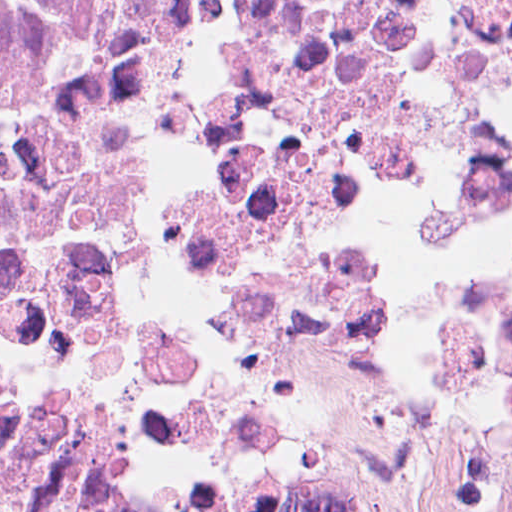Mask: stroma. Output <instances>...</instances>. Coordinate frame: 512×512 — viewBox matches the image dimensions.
<instances>
[{"mask_svg": "<svg viewBox=\"0 0 512 512\" xmlns=\"http://www.w3.org/2000/svg\"><path fill=\"white\" fill-rule=\"evenodd\" d=\"M67 409H150L145 404H91ZM38 415V414H37ZM22 420L16 422L1 440L11 432ZM0 440V441H1Z\"/></svg>", "mask_w": 512, "mask_h": 512, "instance_id": "1", "label": "stroma"}]
</instances>
